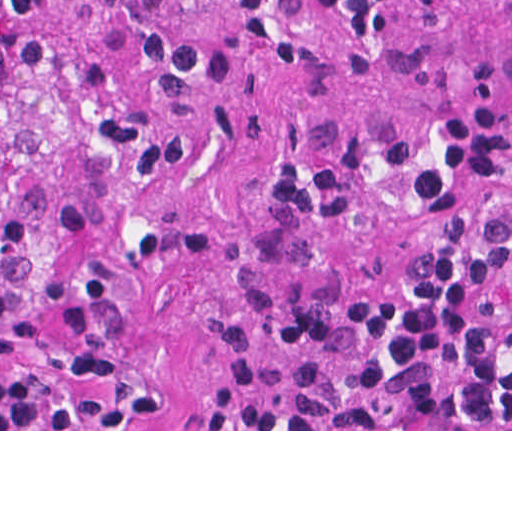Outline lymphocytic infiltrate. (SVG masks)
Returning <instances> with one entry per match:
<instances>
[{
    "label": "lymphocytic infiltrate",
    "instance_id": "obj_1",
    "mask_svg": "<svg viewBox=\"0 0 512 512\" xmlns=\"http://www.w3.org/2000/svg\"><path fill=\"white\" fill-rule=\"evenodd\" d=\"M417 0H313L354 49ZM240 36L293 40L273 0H221ZM273 220L379 226L414 207L431 229L375 305L241 351L217 384L227 429H512V90L464 95L426 139L382 143L273 184Z\"/></svg>",
    "mask_w": 512,
    "mask_h": 512
}]
</instances>
